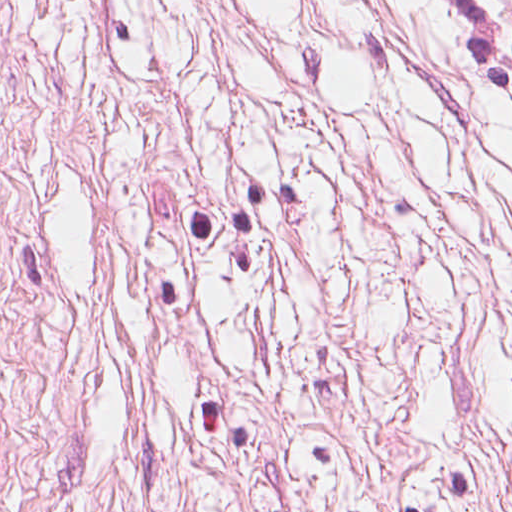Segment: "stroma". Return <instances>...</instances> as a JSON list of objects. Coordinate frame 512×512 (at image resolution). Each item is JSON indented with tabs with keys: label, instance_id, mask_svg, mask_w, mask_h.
Masks as SVG:
<instances>
[{
	"label": "stroma",
	"instance_id": "1",
	"mask_svg": "<svg viewBox=\"0 0 512 512\" xmlns=\"http://www.w3.org/2000/svg\"><path fill=\"white\" fill-rule=\"evenodd\" d=\"M0 512H512V105L15 0Z\"/></svg>",
	"mask_w": 512,
	"mask_h": 512
}]
</instances>
